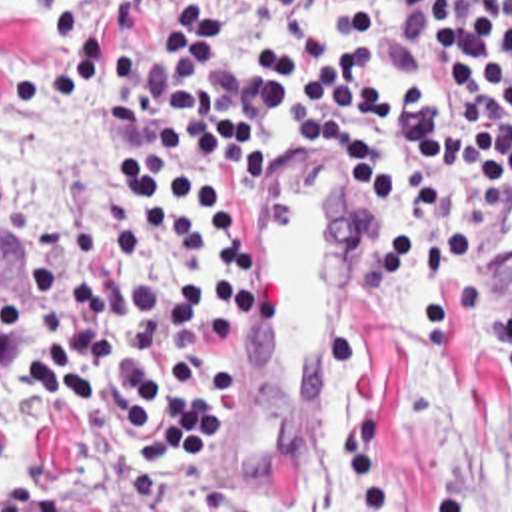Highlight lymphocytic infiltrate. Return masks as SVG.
<instances>
[{"mask_svg":"<svg viewBox=\"0 0 512 512\" xmlns=\"http://www.w3.org/2000/svg\"><path fill=\"white\" fill-rule=\"evenodd\" d=\"M11 111L107 75L113 223L47 229L27 315L0 283V367L31 365L119 461L173 487L232 437L258 369V189L332 191L362 219L354 291L420 261V339L456 359V319L512 383V0H21L37 39L81 31Z\"/></svg>","mask_w":512,"mask_h":512,"instance_id":"lymphocytic-infiltrate-1","label":"lymphocytic infiltrate"}]
</instances>
